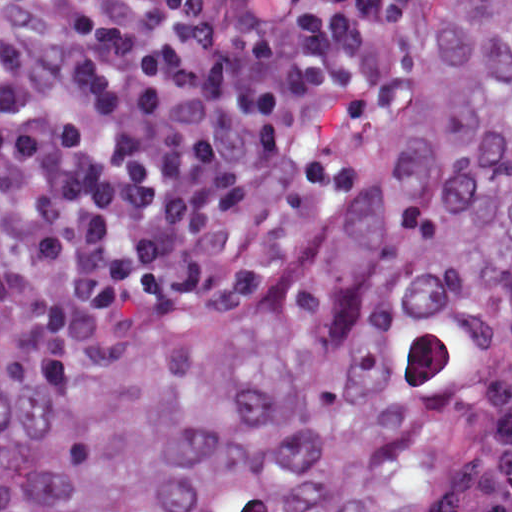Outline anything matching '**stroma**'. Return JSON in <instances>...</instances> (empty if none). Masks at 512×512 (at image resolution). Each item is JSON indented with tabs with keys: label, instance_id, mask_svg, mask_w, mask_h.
<instances>
[{
	"label": "stroma",
	"instance_id": "obj_1",
	"mask_svg": "<svg viewBox=\"0 0 512 512\" xmlns=\"http://www.w3.org/2000/svg\"><path fill=\"white\" fill-rule=\"evenodd\" d=\"M412 91V90H411ZM411 95V92H410ZM408 100L403 112L406 109ZM274 273V272H273ZM272 274V273H271ZM271 274L251 280L235 282L213 290H47L60 301H165L207 294L229 293L251 289ZM26 283V282H25ZM29 284V283H28ZM32 285V284H31ZM35 286V285H33ZM0 512H1V0H0Z\"/></svg>",
	"mask_w": 512,
	"mask_h": 512
}]
</instances>
